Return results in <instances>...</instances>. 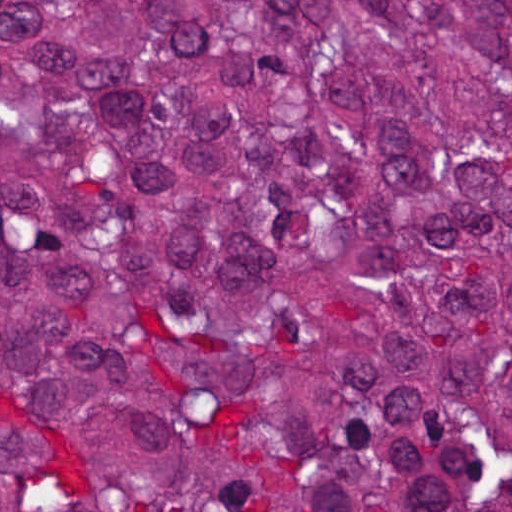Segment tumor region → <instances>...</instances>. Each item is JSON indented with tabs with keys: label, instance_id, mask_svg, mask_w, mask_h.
Here are the masks:
<instances>
[{
	"label": "tumor region",
	"instance_id": "e687c5a6",
	"mask_svg": "<svg viewBox=\"0 0 512 512\" xmlns=\"http://www.w3.org/2000/svg\"><path fill=\"white\" fill-rule=\"evenodd\" d=\"M1 512H512V0H1Z\"/></svg>",
	"mask_w": 512,
	"mask_h": 512
}]
</instances>
